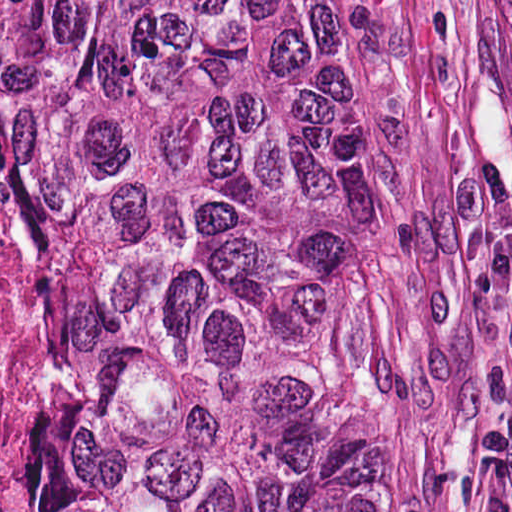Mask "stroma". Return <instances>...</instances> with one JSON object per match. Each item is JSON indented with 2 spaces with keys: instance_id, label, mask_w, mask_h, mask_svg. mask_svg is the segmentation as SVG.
Listing matches in <instances>:
<instances>
[{
  "instance_id": "35a3bbf8",
  "label": "stroma",
  "mask_w": 512,
  "mask_h": 512,
  "mask_svg": "<svg viewBox=\"0 0 512 512\" xmlns=\"http://www.w3.org/2000/svg\"><path fill=\"white\" fill-rule=\"evenodd\" d=\"M343 1L376 84L389 512H512V4Z\"/></svg>"
}]
</instances>
